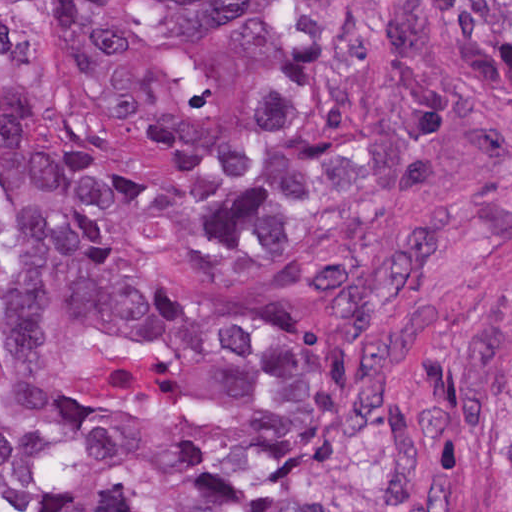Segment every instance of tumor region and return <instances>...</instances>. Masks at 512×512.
I'll use <instances>...</instances> for the list:
<instances>
[{
  "label": "tumor region",
  "mask_w": 512,
  "mask_h": 512,
  "mask_svg": "<svg viewBox=\"0 0 512 512\" xmlns=\"http://www.w3.org/2000/svg\"><path fill=\"white\" fill-rule=\"evenodd\" d=\"M426 3L447 34L415 1H1V512H473L420 484L409 313L512 180V1ZM487 402L512 456V311Z\"/></svg>",
  "instance_id": "obj_1"
}]
</instances>
